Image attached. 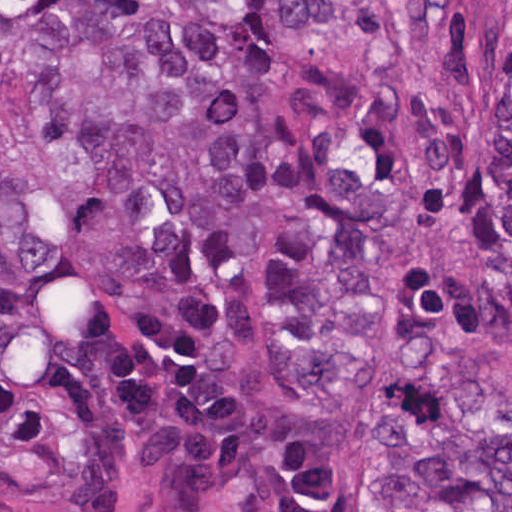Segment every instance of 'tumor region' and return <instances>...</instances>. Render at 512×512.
I'll use <instances>...</instances> for the list:
<instances>
[{"label":"tumor region","instance_id":"e687c5a6","mask_svg":"<svg viewBox=\"0 0 512 512\" xmlns=\"http://www.w3.org/2000/svg\"><path fill=\"white\" fill-rule=\"evenodd\" d=\"M473 0H1V512H357L397 269L485 135ZM361 512H512V30Z\"/></svg>","mask_w":512,"mask_h":512}]
</instances>
